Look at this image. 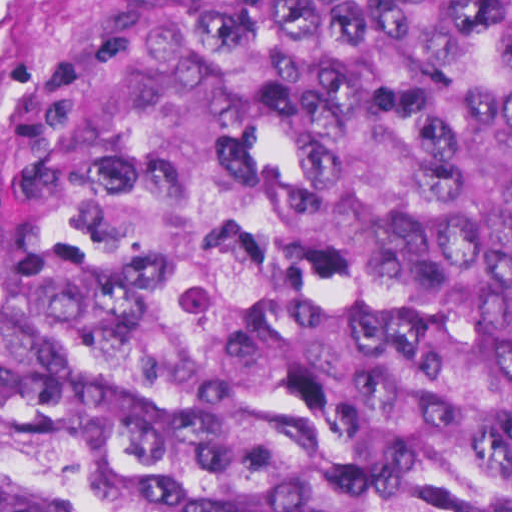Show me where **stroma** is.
I'll return each instance as SVG.
<instances>
[{
  "mask_svg": "<svg viewBox=\"0 0 512 512\" xmlns=\"http://www.w3.org/2000/svg\"><path fill=\"white\" fill-rule=\"evenodd\" d=\"M146 0H0V180L33 118Z\"/></svg>",
  "mask_w": 512,
  "mask_h": 512,
  "instance_id": "obj_1",
  "label": "stroma"
}]
</instances>
